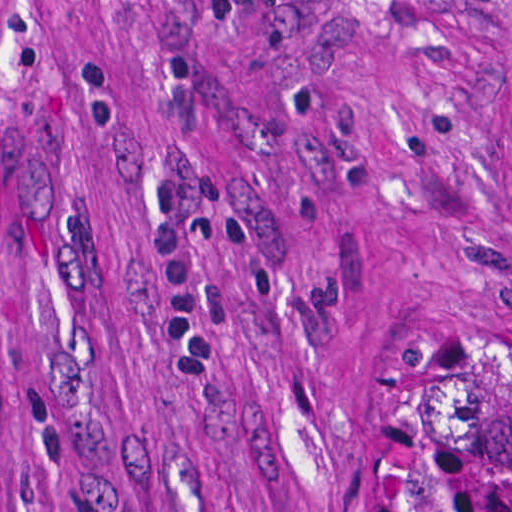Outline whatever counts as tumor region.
<instances>
[{
    "mask_svg": "<svg viewBox=\"0 0 512 512\" xmlns=\"http://www.w3.org/2000/svg\"><path fill=\"white\" fill-rule=\"evenodd\" d=\"M376 512H512V304L387 319L364 365Z\"/></svg>",
    "mask_w": 512,
    "mask_h": 512,
    "instance_id": "1",
    "label": "tumor region"
}]
</instances>
